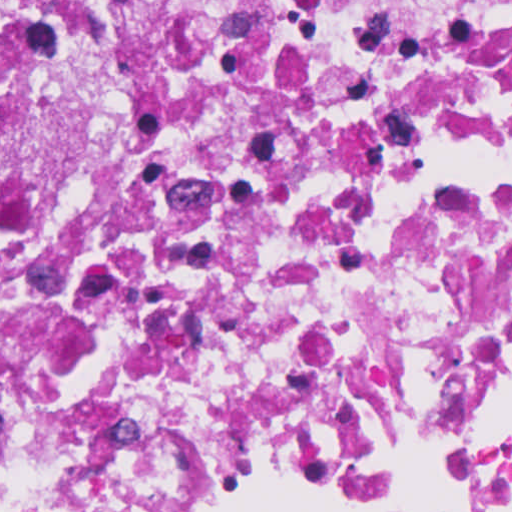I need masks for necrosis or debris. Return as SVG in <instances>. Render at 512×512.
Here are the masks:
<instances>
[{
    "instance_id": "4bbe7bcc",
    "label": "necrosis or debris",
    "mask_w": 512,
    "mask_h": 512,
    "mask_svg": "<svg viewBox=\"0 0 512 512\" xmlns=\"http://www.w3.org/2000/svg\"><path fill=\"white\" fill-rule=\"evenodd\" d=\"M180 501L512 512V0H0V512Z\"/></svg>"
}]
</instances>
